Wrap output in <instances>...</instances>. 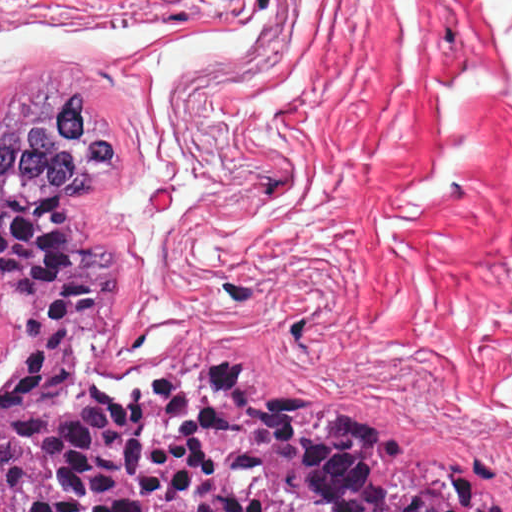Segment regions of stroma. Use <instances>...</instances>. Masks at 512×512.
<instances>
[{"label":"stroma","mask_w":512,"mask_h":512,"mask_svg":"<svg viewBox=\"0 0 512 512\" xmlns=\"http://www.w3.org/2000/svg\"><path fill=\"white\" fill-rule=\"evenodd\" d=\"M84 88L120 380L248 353L512 486V0H0V128Z\"/></svg>","instance_id":"1"}]
</instances>
